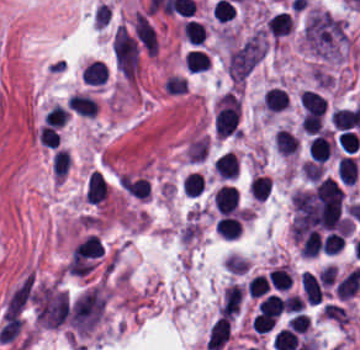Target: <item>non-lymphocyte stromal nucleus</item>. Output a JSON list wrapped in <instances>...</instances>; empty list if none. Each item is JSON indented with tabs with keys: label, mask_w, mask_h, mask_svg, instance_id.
<instances>
[{
	"label": "non-lymphocyte stromal nucleus",
	"mask_w": 360,
	"mask_h": 350,
	"mask_svg": "<svg viewBox=\"0 0 360 350\" xmlns=\"http://www.w3.org/2000/svg\"><path fill=\"white\" fill-rule=\"evenodd\" d=\"M301 43L312 53L342 54L349 35L341 18L322 6H308L300 20Z\"/></svg>",
	"instance_id": "dd21d789"
},
{
	"label": "non-lymphocyte stromal nucleus",
	"mask_w": 360,
	"mask_h": 350,
	"mask_svg": "<svg viewBox=\"0 0 360 350\" xmlns=\"http://www.w3.org/2000/svg\"><path fill=\"white\" fill-rule=\"evenodd\" d=\"M265 44V32L260 28L229 49L226 68L233 85L245 81L259 61Z\"/></svg>",
	"instance_id": "a72fc3eb"
},
{
	"label": "non-lymphocyte stromal nucleus",
	"mask_w": 360,
	"mask_h": 350,
	"mask_svg": "<svg viewBox=\"0 0 360 350\" xmlns=\"http://www.w3.org/2000/svg\"><path fill=\"white\" fill-rule=\"evenodd\" d=\"M112 51L117 68L132 82L138 69L137 39L121 23L112 36Z\"/></svg>",
	"instance_id": "3746e769"
},
{
	"label": "non-lymphocyte stromal nucleus",
	"mask_w": 360,
	"mask_h": 350,
	"mask_svg": "<svg viewBox=\"0 0 360 350\" xmlns=\"http://www.w3.org/2000/svg\"><path fill=\"white\" fill-rule=\"evenodd\" d=\"M133 33L142 46L155 55L158 49L156 33L145 14L137 10L133 16Z\"/></svg>",
	"instance_id": "fc2b8d12"
},
{
	"label": "non-lymphocyte stromal nucleus",
	"mask_w": 360,
	"mask_h": 350,
	"mask_svg": "<svg viewBox=\"0 0 360 350\" xmlns=\"http://www.w3.org/2000/svg\"><path fill=\"white\" fill-rule=\"evenodd\" d=\"M244 289L237 283H229L224 289L218 314L224 317H231L235 314L243 298Z\"/></svg>",
	"instance_id": "81446118"
},
{
	"label": "non-lymphocyte stromal nucleus",
	"mask_w": 360,
	"mask_h": 350,
	"mask_svg": "<svg viewBox=\"0 0 360 350\" xmlns=\"http://www.w3.org/2000/svg\"><path fill=\"white\" fill-rule=\"evenodd\" d=\"M229 318L219 316L209 327L205 341V348L211 350L221 349L229 336Z\"/></svg>",
	"instance_id": "7c5642bf"
},
{
	"label": "non-lymphocyte stromal nucleus",
	"mask_w": 360,
	"mask_h": 350,
	"mask_svg": "<svg viewBox=\"0 0 360 350\" xmlns=\"http://www.w3.org/2000/svg\"><path fill=\"white\" fill-rule=\"evenodd\" d=\"M300 284L303 296L310 303L317 304L322 301L323 291L319 275L309 270H302L300 274Z\"/></svg>",
	"instance_id": "9d01c50a"
}]
</instances>
